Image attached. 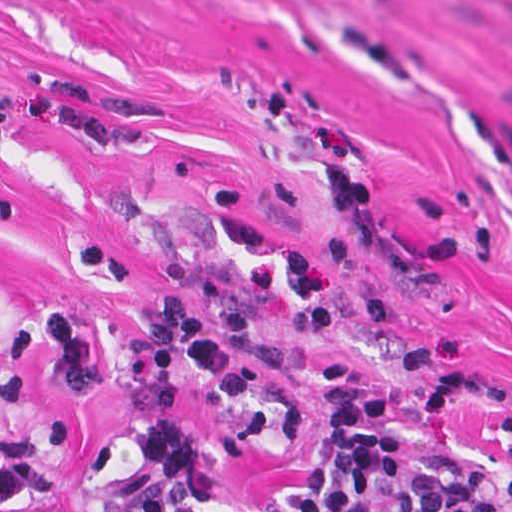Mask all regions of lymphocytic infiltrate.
Here are the masks:
<instances>
[{
    "instance_id": "1",
    "label": "lymphocytic infiltrate",
    "mask_w": 512,
    "mask_h": 512,
    "mask_svg": "<svg viewBox=\"0 0 512 512\" xmlns=\"http://www.w3.org/2000/svg\"><path fill=\"white\" fill-rule=\"evenodd\" d=\"M156 311L161 318L123 344L99 339L77 306L47 307L24 322L13 340L9 379L0 384V507L33 502L76 458L70 414L26 427L33 357L52 364L76 402L96 392L101 366L121 393L135 425L134 462L113 512H163L194 486L201 463L182 385L189 380L256 435L425 423L444 413L467 382L466 363L374 383L326 360L319 398L298 413L274 403L255 375L295 351L293 342L255 331L248 290H229L203 305L168 282ZM166 512H512V456H445L344 437L322 443L296 489L201 493Z\"/></svg>"
}]
</instances>
